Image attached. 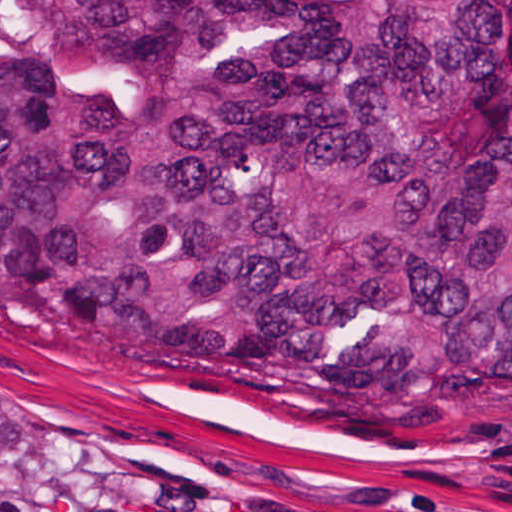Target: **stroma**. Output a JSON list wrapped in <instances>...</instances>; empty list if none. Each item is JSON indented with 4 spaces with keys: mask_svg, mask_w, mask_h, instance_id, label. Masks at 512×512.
<instances>
[{
    "mask_svg": "<svg viewBox=\"0 0 512 512\" xmlns=\"http://www.w3.org/2000/svg\"><path fill=\"white\" fill-rule=\"evenodd\" d=\"M0 512H512V394L259 411L97 374L0 337Z\"/></svg>",
    "mask_w": 512,
    "mask_h": 512,
    "instance_id": "stroma-1",
    "label": "stroma"
}]
</instances>
